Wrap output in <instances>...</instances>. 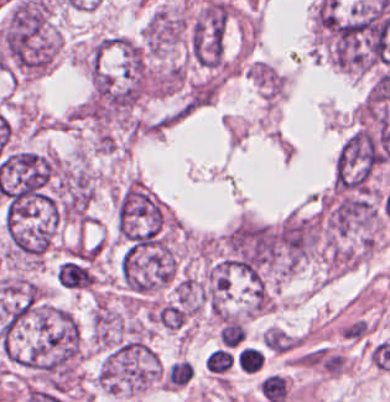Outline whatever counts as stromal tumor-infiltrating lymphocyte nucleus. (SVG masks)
<instances>
[{
  "instance_id": "bc302bb0",
  "label": "stromal tumor-infiltrating lymphocyte nucleus",
  "mask_w": 390,
  "mask_h": 402,
  "mask_svg": "<svg viewBox=\"0 0 390 402\" xmlns=\"http://www.w3.org/2000/svg\"><path fill=\"white\" fill-rule=\"evenodd\" d=\"M236 355L227 346H220L211 353L206 359V369L214 375H225L234 364Z\"/></svg>"
},
{
  "instance_id": "52c7bb5b",
  "label": "stromal tumor-infiltrating lymphocyte nucleus",
  "mask_w": 390,
  "mask_h": 402,
  "mask_svg": "<svg viewBox=\"0 0 390 402\" xmlns=\"http://www.w3.org/2000/svg\"><path fill=\"white\" fill-rule=\"evenodd\" d=\"M237 364L246 372H254L261 369L263 356L256 349L244 348L237 356Z\"/></svg>"
},
{
  "instance_id": "3290ff9b",
  "label": "stromal tumor-infiltrating lymphocyte nucleus",
  "mask_w": 390,
  "mask_h": 402,
  "mask_svg": "<svg viewBox=\"0 0 390 402\" xmlns=\"http://www.w3.org/2000/svg\"><path fill=\"white\" fill-rule=\"evenodd\" d=\"M242 340V324L237 320H230L222 329L221 342L227 347H235Z\"/></svg>"
}]
</instances>
